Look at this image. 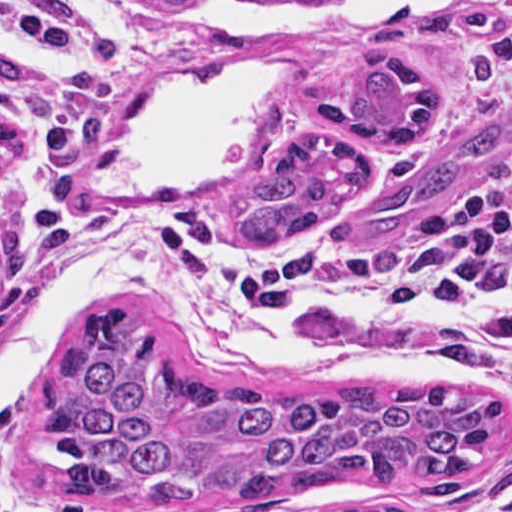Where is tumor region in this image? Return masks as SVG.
Segmentation results:
<instances>
[{
	"mask_svg": "<svg viewBox=\"0 0 512 512\" xmlns=\"http://www.w3.org/2000/svg\"><path fill=\"white\" fill-rule=\"evenodd\" d=\"M143 1L184 10L204 0ZM317 107L332 127L395 143L401 160L373 185L376 163L350 135L296 133L235 209L233 244L273 250L354 204L359 228L398 223L512 143L510 98L423 154L447 97L439 76L404 53L346 60L327 77ZM13 141L14 122L0 114V161ZM34 410L65 448L67 491L85 501H259L352 479L454 497L502 431V398L471 385L270 390L197 379L159 353L143 323L86 329L62 349Z\"/></svg>",
	"mask_w": 512,
	"mask_h": 512,
	"instance_id": "1",
	"label": "tumor region"
}]
</instances>
